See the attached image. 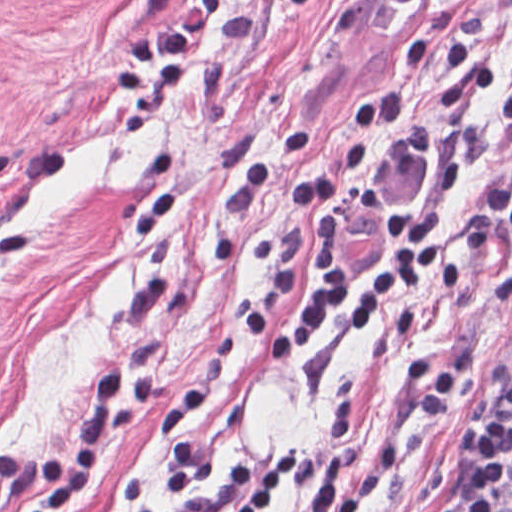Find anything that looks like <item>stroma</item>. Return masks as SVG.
<instances>
[{
	"label": "stroma",
	"mask_w": 512,
	"mask_h": 512,
	"mask_svg": "<svg viewBox=\"0 0 512 512\" xmlns=\"http://www.w3.org/2000/svg\"><path fill=\"white\" fill-rule=\"evenodd\" d=\"M511 174L512 0H0V454L60 457L94 373L148 364V418L58 512H179L292 444L263 512H444L512 380ZM420 209L459 291L236 338Z\"/></svg>",
	"instance_id": "1"
}]
</instances>
